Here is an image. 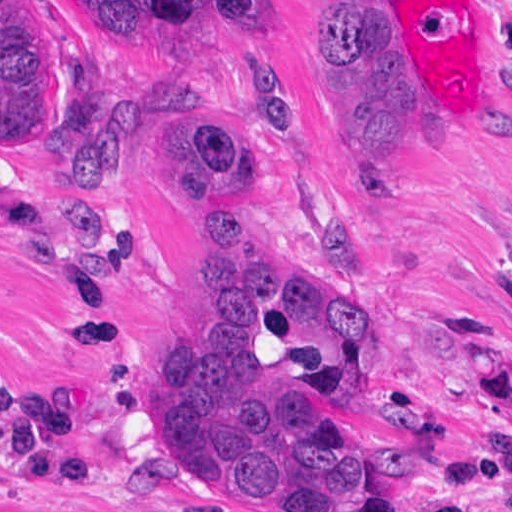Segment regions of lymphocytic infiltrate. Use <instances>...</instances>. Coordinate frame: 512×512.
<instances>
[{"mask_svg": "<svg viewBox=\"0 0 512 512\" xmlns=\"http://www.w3.org/2000/svg\"><path fill=\"white\" fill-rule=\"evenodd\" d=\"M0 462L55 488H115L93 459L72 393L0 377Z\"/></svg>", "mask_w": 512, "mask_h": 512, "instance_id": "1", "label": "lymphocytic infiltrate"}]
</instances>
